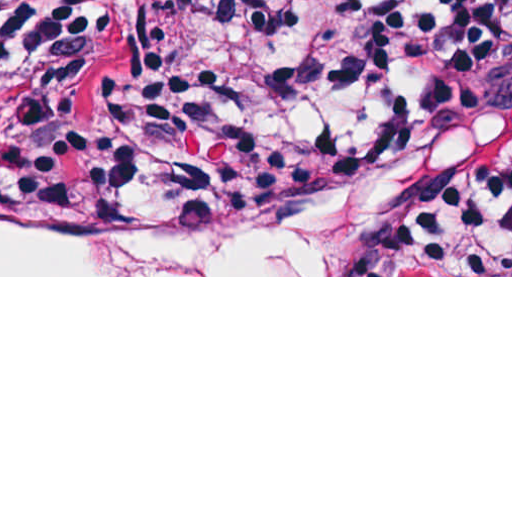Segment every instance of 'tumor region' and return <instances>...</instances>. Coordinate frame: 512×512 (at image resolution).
Segmentation results:
<instances>
[{
  "label": "tumor region",
  "instance_id": "1",
  "mask_svg": "<svg viewBox=\"0 0 512 512\" xmlns=\"http://www.w3.org/2000/svg\"><path fill=\"white\" fill-rule=\"evenodd\" d=\"M157 2L160 7L179 4V0ZM510 28L512 0L456 7L433 17L425 27V48L409 99L406 136L386 148L354 158L315 194L357 174L386 169L425 170L447 188L435 216L414 237L429 257L459 275L450 247V228L464 209L512 174V120L501 127L482 130L433 127L427 111V86L433 71L459 51ZM67 92L36 88L29 70V34L11 31L0 36V115L19 103L59 100ZM0 175L30 177L8 163L1 153Z\"/></svg>",
  "mask_w": 512,
  "mask_h": 512
}]
</instances>
